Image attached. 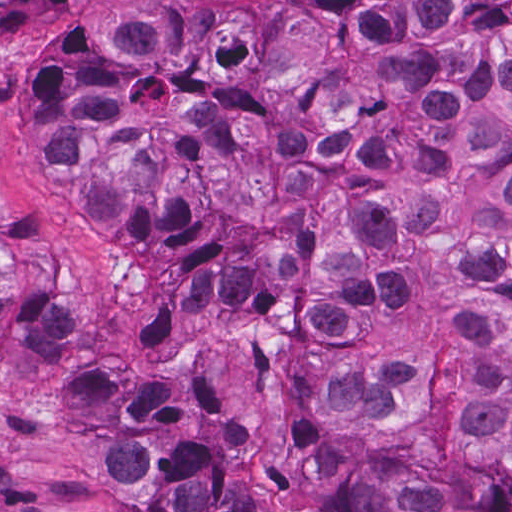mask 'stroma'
Returning <instances> with one entry per match:
<instances>
[{"label":"stroma","instance_id":"1","mask_svg":"<svg viewBox=\"0 0 512 512\" xmlns=\"http://www.w3.org/2000/svg\"><path fill=\"white\" fill-rule=\"evenodd\" d=\"M100 0L0 2V314L42 310L150 362H197L236 396L234 462L265 475L288 512H338L297 426L298 352L276 328L230 314L149 243L73 212L40 140L47 66ZM57 356L0 343V512H111L82 445L39 399Z\"/></svg>","mask_w":512,"mask_h":512}]
</instances>
